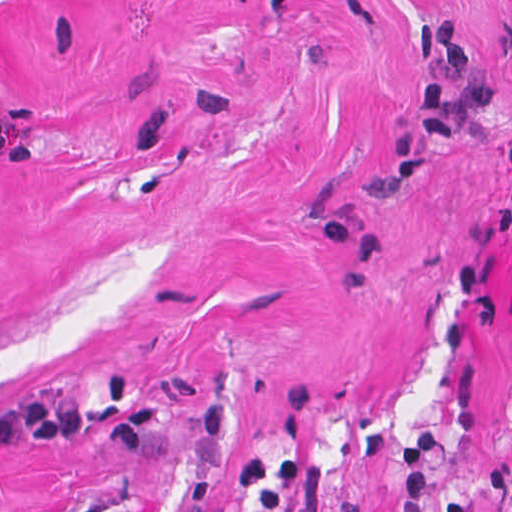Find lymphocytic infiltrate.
Wrapping results in <instances>:
<instances>
[{
  "instance_id": "lymphocytic-infiltrate-1",
  "label": "lymphocytic infiltrate",
  "mask_w": 512,
  "mask_h": 512,
  "mask_svg": "<svg viewBox=\"0 0 512 512\" xmlns=\"http://www.w3.org/2000/svg\"><path fill=\"white\" fill-rule=\"evenodd\" d=\"M431 75L417 101L423 126L435 134H456L464 118L485 112L512 97V71L484 69L466 48L458 21L427 26L416 41ZM89 425V414L78 404L57 402L42 390L23 396L0 412V446L34 442L68 446Z\"/></svg>"
}]
</instances>
